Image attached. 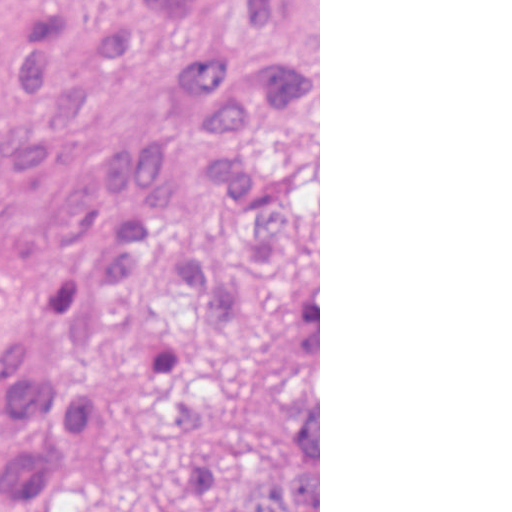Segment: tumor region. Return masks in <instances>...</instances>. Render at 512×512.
I'll list each match as a JSON object with an SVG mask.
<instances>
[{
  "label": "tumor region",
  "mask_w": 512,
  "mask_h": 512,
  "mask_svg": "<svg viewBox=\"0 0 512 512\" xmlns=\"http://www.w3.org/2000/svg\"><path fill=\"white\" fill-rule=\"evenodd\" d=\"M150 48L193 131L128 135L92 173L128 171L148 225L107 279L135 280L201 165L252 248L319 205V0H0V175L77 157L100 68ZM315 267L254 274L227 244L179 252L175 315L116 329L92 303L4 428L0 512H93L124 446L127 407L160 389L191 465V512H319V293Z\"/></svg>",
  "instance_id": "tumor-region-1"
}]
</instances>
